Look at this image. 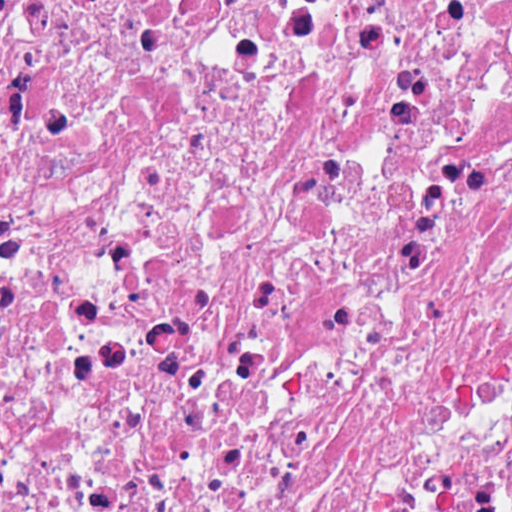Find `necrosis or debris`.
Segmentation results:
<instances>
[{
    "instance_id": "obj_1",
    "label": "necrosis or debris",
    "mask_w": 512,
    "mask_h": 512,
    "mask_svg": "<svg viewBox=\"0 0 512 512\" xmlns=\"http://www.w3.org/2000/svg\"><path fill=\"white\" fill-rule=\"evenodd\" d=\"M0 512H512V0H0Z\"/></svg>"
}]
</instances>
